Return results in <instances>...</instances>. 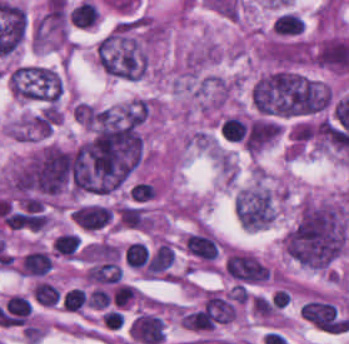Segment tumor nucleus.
<instances>
[{
    "label": "tumor nucleus",
    "mask_w": 349,
    "mask_h": 344,
    "mask_svg": "<svg viewBox=\"0 0 349 344\" xmlns=\"http://www.w3.org/2000/svg\"><path fill=\"white\" fill-rule=\"evenodd\" d=\"M347 229L343 208L306 201L283 239L284 252L297 265L325 271L345 251Z\"/></svg>",
    "instance_id": "1"
},
{
    "label": "tumor nucleus",
    "mask_w": 349,
    "mask_h": 344,
    "mask_svg": "<svg viewBox=\"0 0 349 344\" xmlns=\"http://www.w3.org/2000/svg\"><path fill=\"white\" fill-rule=\"evenodd\" d=\"M235 213L241 226L256 231L266 228L276 213L272 192L259 185L242 188L235 196Z\"/></svg>",
    "instance_id": "2"
},
{
    "label": "tumor nucleus",
    "mask_w": 349,
    "mask_h": 344,
    "mask_svg": "<svg viewBox=\"0 0 349 344\" xmlns=\"http://www.w3.org/2000/svg\"><path fill=\"white\" fill-rule=\"evenodd\" d=\"M280 132L281 126L276 123L262 119H255L251 122L243 137L247 151H261Z\"/></svg>",
    "instance_id": "3"
}]
</instances>
